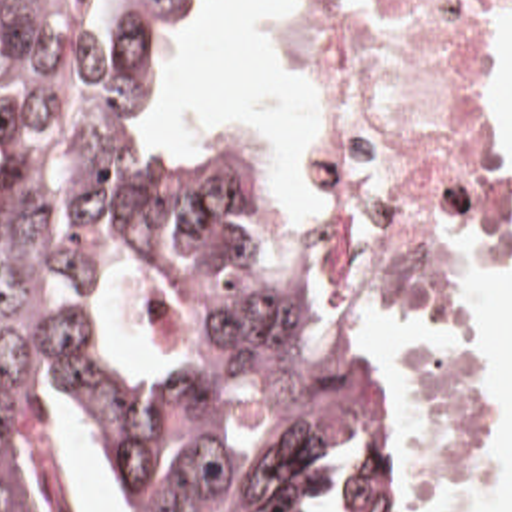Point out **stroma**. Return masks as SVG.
<instances>
[{
    "label": "stroma",
    "mask_w": 512,
    "mask_h": 512,
    "mask_svg": "<svg viewBox=\"0 0 512 512\" xmlns=\"http://www.w3.org/2000/svg\"><path fill=\"white\" fill-rule=\"evenodd\" d=\"M61 1L85 7L97 0ZM201 23L185 33H169L157 21L161 41H163V67L157 69L153 75H149V99H147L145 119H147L151 131L179 147H229V149L245 153V155L257 159L259 163L267 165L269 169H273L277 175L279 187H281L285 213H287V225H289L291 241L295 247V271H297L311 303L315 305L323 325L337 339L383 359L391 367V363L385 359V355L379 351V347L373 341H369L365 335H361L357 329H353L349 323H345L325 295L319 261H317V251H315V241H313V229H311V217H309V205H307V193H305V177H301L295 183H285L279 159L271 145H267L259 139H251V137L217 133L205 125H181L179 119L175 117V113L171 111L169 87L177 75L181 57H183L185 49L189 47V43L193 41V37L197 35ZM267 53H269L271 73L277 75L281 81H285L305 101V45H303L297 0H279L277 3L275 31L267 43ZM496 63H498V57H496ZM494 73H496V65H494ZM492 85H494V75H492ZM490 97H492V87H490ZM506 179H508V191H510V239L500 249V253L494 257V261L488 265V269L482 273V277L476 281L468 299L490 277L512 273V179L508 175H506ZM468 299L458 317V361L466 373V379H468V383L472 387V395H474L476 417H478V460L466 472H462L454 482L421 480V478H413V474L395 442V512H422L426 500H430V498H436V496H442V494L488 480L492 474H496L500 470V466L508 454V405L502 403L498 397H494L486 389V385L474 373V369L464 353V313H466Z\"/></svg>",
    "instance_id": "obj_1"
}]
</instances>
